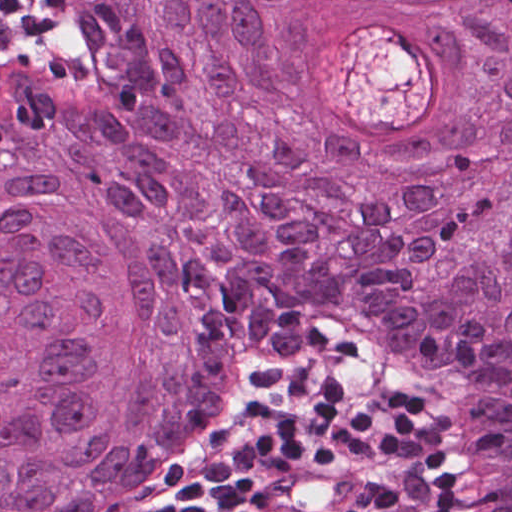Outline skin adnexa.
Segmentation results:
<instances>
[{"label": "skin adnexa", "instance_id": "bc48264e", "mask_svg": "<svg viewBox=\"0 0 512 512\" xmlns=\"http://www.w3.org/2000/svg\"><path fill=\"white\" fill-rule=\"evenodd\" d=\"M0 71V512H151L252 365L353 329L465 389L512 512V0H44Z\"/></svg>", "mask_w": 512, "mask_h": 512}]
</instances>
